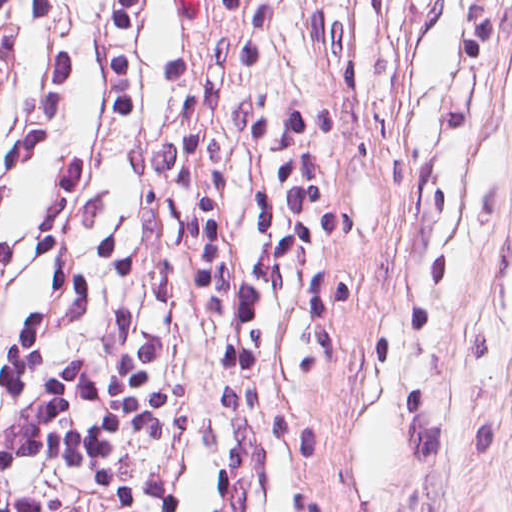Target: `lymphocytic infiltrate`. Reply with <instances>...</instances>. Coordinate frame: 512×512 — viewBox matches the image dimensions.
<instances>
[{"label": "lymphocytic infiltrate", "mask_w": 512, "mask_h": 512, "mask_svg": "<svg viewBox=\"0 0 512 512\" xmlns=\"http://www.w3.org/2000/svg\"><path fill=\"white\" fill-rule=\"evenodd\" d=\"M309 449L213 1L0 0V512H311Z\"/></svg>", "instance_id": "obj_1"}]
</instances>
